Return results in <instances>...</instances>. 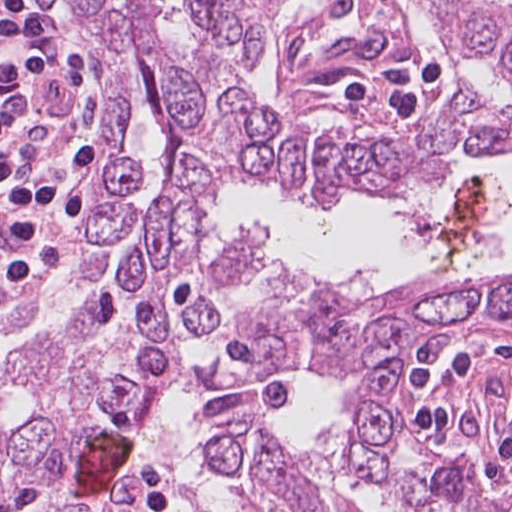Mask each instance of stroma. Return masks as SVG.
I'll return each mask as SVG.
<instances>
[{
    "label": "stroma",
    "instance_id": "35a3bbf8",
    "mask_svg": "<svg viewBox=\"0 0 512 512\" xmlns=\"http://www.w3.org/2000/svg\"><path fill=\"white\" fill-rule=\"evenodd\" d=\"M388 361L401 370L393 388L401 427L388 452V472L396 478L468 473L482 482L481 512H490L512 480V323H451L360 368L277 371L288 399L279 432L324 466L363 512H422L387 482L347 475L331 459L349 390ZM217 396L214 391L203 408ZM162 451L194 512L163 442ZM166 504L187 512L175 502H163L156 512Z\"/></svg>",
    "mask_w": 512,
    "mask_h": 512
}]
</instances>
